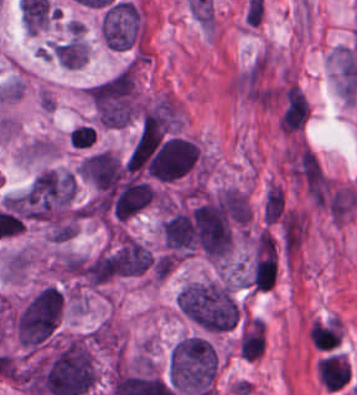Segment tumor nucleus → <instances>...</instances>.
<instances>
[{
    "label": "tumor nucleus",
    "mask_w": 357,
    "mask_h": 395,
    "mask_svg": "<svg viewBox=\"0 0 357 395\" xmlns=\"http://www.w3.org/2000/svg\"><path fill=\"white\" fill-rule=\"evenodd\" d=\"M61 287L45 284L28 297L15 317V336L20 342H45L53 336L63 315Z\"/></svg>",
    "instance_id": "3"
},
{
    "label": "tumor nucleus",
    "mask_w": 357,
    "mask_h": 395,
    "mask_svg": "<svg viewBox=\"0 0 357 395\" xmlns=\"http://www.w3.org/2000/svg\"><path fill=\"white\" fill-rule=\"evenodd\" d=\"M218 357L206 337L185 335L170 348L167 380L181 393L212 395Z\"/></svg>",
    "instance_id": "1"
},
{
    "label": "tumor nucleus",
    "mask_w": 357,
    "mask_h": 395,
    "mask_svg": "<svg viewBox=\"0 0 357 395\" xmlns=\"http://www.w3.org/2000/svg\"><path fill=\"white\" fill-rule=\"evenodd\" d=\"M176 303L190 320L210 331L230 327L238 314L233 288L225 280H193L181 286Z\"/></svg>",
    "instance_id": "2"
}]
</instances>
